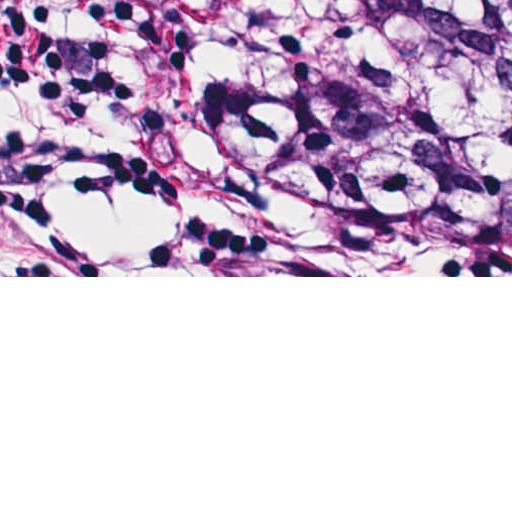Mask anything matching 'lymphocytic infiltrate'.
I'll use <instances>...</instances> for the list:
<instances>
[{"mask_svg":"<svg viewBox=\"0 0 512 512\" xmlns=\"http://www.w3.org/2000/svg\"><path fill=\"white\" fill-rule=\"evenodd\" d=\"M0 94L101 132L105 181L156 209L146 242L109 245L55 216L52 161L0 146V276H239L204 198L152 125L101 0H0Z\"/></svg>","mask_w":512,"mask_h":512,"instance_id":"f902f5d3","label":"lymphocytic infiltrate"}]
</instances>
